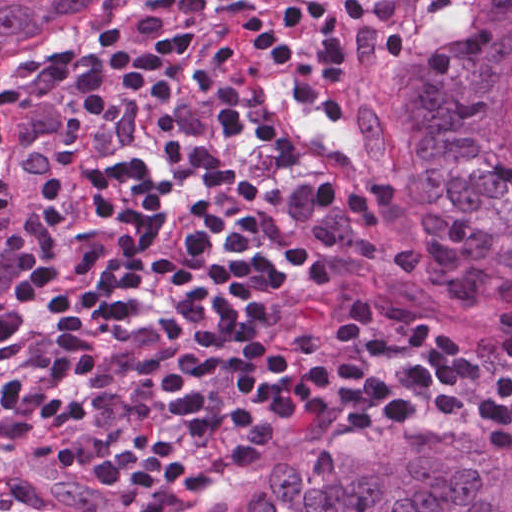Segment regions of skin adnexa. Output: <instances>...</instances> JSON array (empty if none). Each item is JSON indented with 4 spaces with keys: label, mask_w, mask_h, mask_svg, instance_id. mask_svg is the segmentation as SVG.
I'll list each match as a JSON object with an SVG mask.
<instances>
[{
    "label": "skin adnexa",
    "mask_w": 512,
    "mask_h": 512,
    "mask_svg": "<svg viewBox=\"0 0 512 512\" xmlns=\"http://www.w3.org/2000/svg\"><path fill=\"white\" fill-rule=\"evenodd\" d=\"M149 0H0V75L61 54ZM407 116L408 174L384 175L379 215L416 297L512 310V0L450 9ZM253 479L196 512H512V450L483 451L458 419L427 416Z\"/></svg>",
    "instance_id": "bc48264e"
}]
</instances>
